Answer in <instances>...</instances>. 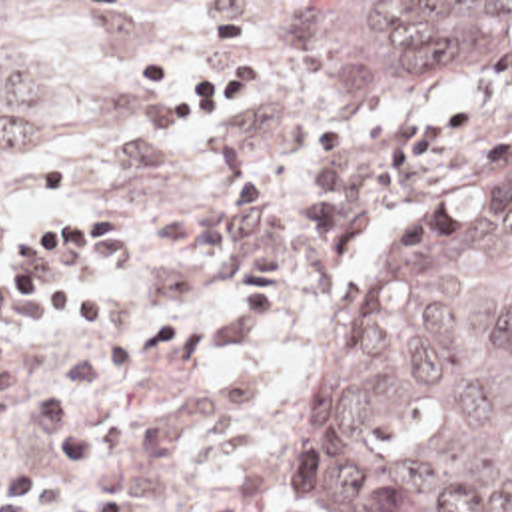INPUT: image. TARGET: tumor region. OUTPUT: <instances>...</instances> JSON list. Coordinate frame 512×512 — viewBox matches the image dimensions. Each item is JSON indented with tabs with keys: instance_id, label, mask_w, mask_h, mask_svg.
Wrapping results in <instances>:
<instances>
[{
	"instance_id": "obj_1",
	"label": "tumor region",
	"mask_w": 512,
	"mask_h": 512,
	"mask_svg": "<svg viewBox=\"0 0 512 512\" xmlns=\"http://www.w3.org/2000/svg\"><path fill=\"white\" fill-rule=\"evenodd\" d=\"M47 2H0V202L43 156ZM327 100L424 108L512 64V2H297ZM299 512H512V144L380 254L303 427Z\"/></svg>"
}]
</instances>
